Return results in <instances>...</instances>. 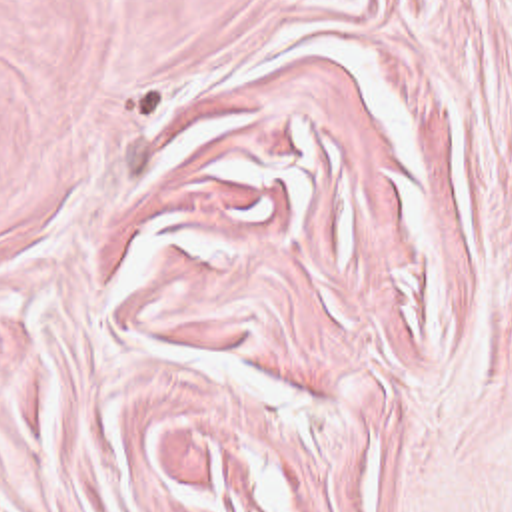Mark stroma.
<instances>
[{
  "mask_svg": "<svg viewBox=\"0 0 512 512\" xmlns=\"http://www.w3.org/2000/svg\"><path fill=\"white\" fill-rule=\"evenodd\" d=\"M0 512H512V0H0Z\"/></svg>",
  "mask_w": 512,
  "mask_h": 512,
  "instance_id": "obj_1",
  "label": "stroma"
}]
</instances>
